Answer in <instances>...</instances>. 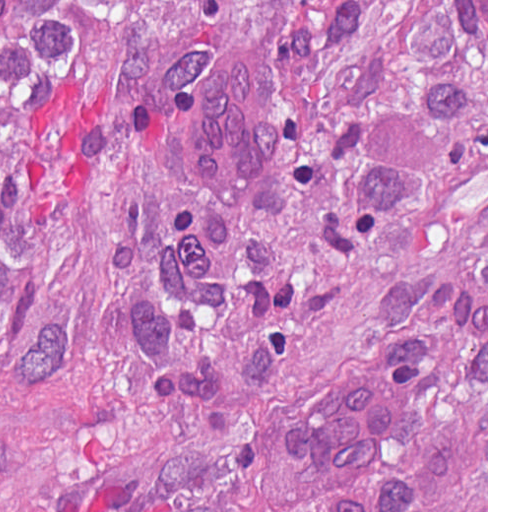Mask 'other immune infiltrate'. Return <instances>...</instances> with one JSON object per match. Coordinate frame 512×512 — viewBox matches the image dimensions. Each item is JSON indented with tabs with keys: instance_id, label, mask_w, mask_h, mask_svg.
I'll return each instance as SVG.
<instances>
[{
	"instance_id": "obj_1",
	"label": "other immune infiltrate",
	"mask_w": 512,
	"mask_h": 512,
	"mask_svg": "<svg viewBox=\"0 0 512 512\" xmlns=\"http://www.w3.org/2000/svg\"><path fill=\"white\" fill-rule=\"evenodd\" d=\"M399 410V392L381 368L339 381L296 419V451L303 469L323 487L359 484Z\"/></svg>"
}]
</instances>
